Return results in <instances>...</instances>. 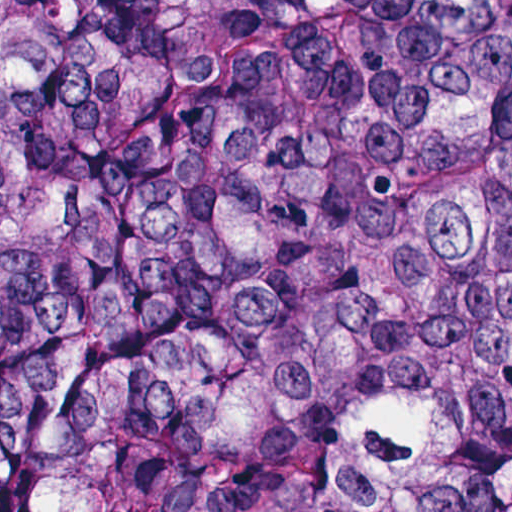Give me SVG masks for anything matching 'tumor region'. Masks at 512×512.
Here are the masks:
<instances>
[{"instance_id": "e687c5a6", "label": "tumor region", "mask_w": 512, "mask_h": 512, "mask_svg": "<svg viewBox=\"0 0 512 512\" xmlns=\"http://www.w3.org/2000/svg\"><path fill=\"white\" fill-rule=\"evenodd\" d=\"M0 512H512V0H0Z\"/></svg>"}]
</instances>
